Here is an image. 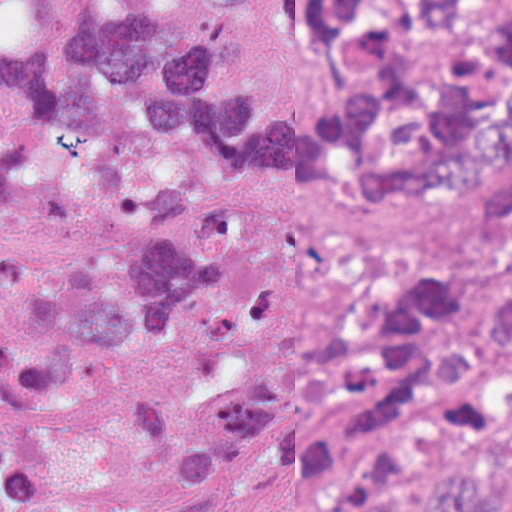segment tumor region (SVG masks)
Here are the masks:
<instances>
[{
	"label": "tumor region",
	"instance_id": "obj_1",
	"mask_svg": "<svg viewBox=\"0 0 512 512\" xmlns=\"http://www.w3.org/2000/svg\"><path fill=\"white\" fill-rule=\"evenodd\" d=\"M244 0H0V512H111L68 480L56 416L86 361L156 355L271 316L236 196L182 210L197 158L290 205L465 209L457 271H392L279 362L142 389L144 463L216 512L303 476L312 512H512V0H287L322 59L311 102L240 64Z\"/></svg>",
	"mask_w": 512,
	"mask_h": 512
}]
</instances>
